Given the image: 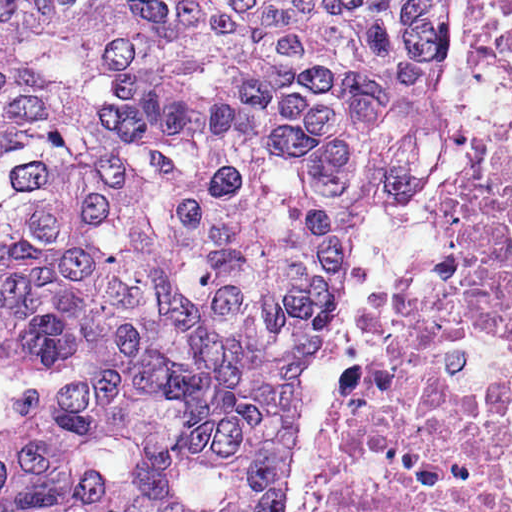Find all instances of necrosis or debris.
<instances>
[{"label": "necrosis or debris", "mask_w": 512, "mask_h": 512, "mask_svg": "<svg viewBox=\"0 0 512 512\" xmlns=\"http://www.w3.org/2000/svg\"><path fill=\"white\" fill-rule=\"evenodd\" d=\"M509 107L424 270L333 412L318 512H512V0L485 13Z\"/></svg>", "instance_id": "obj_1"}]
</instances>
